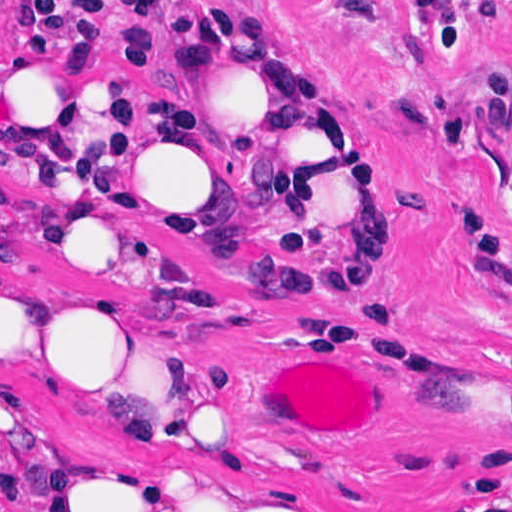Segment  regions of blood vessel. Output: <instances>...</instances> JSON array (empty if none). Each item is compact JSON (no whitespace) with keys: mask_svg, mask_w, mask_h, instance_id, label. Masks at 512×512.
Instances as JSON below:
<instances>
[{"mask_svg":"<svg viewBox=\"0 0 512 512\" xmlns=\"http://www.w3.org/2000/svg\"><path fill=\"white\" fill-rule=\"evenodd\" d=\"M330 363H285L267 379V418L276 431L305 441H351L374 421V401L360 375Z\"/></svg>","mask_w":512,"mask_h":512,"instance_id":"blood-vessel-1","label":"blood vessel"}]
</instances>
